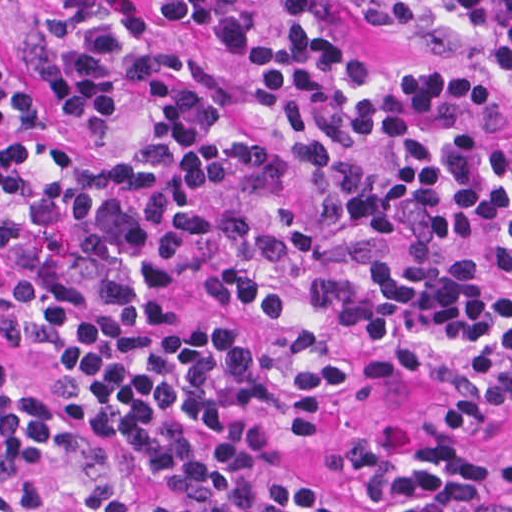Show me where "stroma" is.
<instances>
[{
  "mask_svg": "<svg viewBox=\"0 0 512 512\" xmlns=\"http://www.w3.org/2000/svg\"><path fill=\"white\" fill-rule=\"evenodd\" d=\"M145 10L148 0H122ZM278 23L310 4H326L347 53L360 63L397 61V28L360 9L351 0H247ZM62 0H0V109L11 123L32 126L58 152L75 149L59 113L41 83L44 22ZM0 351L30 390L58 385L71 358L48 340L21 327L0 326ZM512 378V362H431L386 359L364 378L333 426L289 440L303 469L331 496L361 500L334 469L336 444L384 418L426 411L450 399L492 390Z\"/></svg>",
  "mask_w": 512,
  "mask_h": 512,
  "instance_id": "stroma-1",
  "label": "stroma"
}]
</instances>
